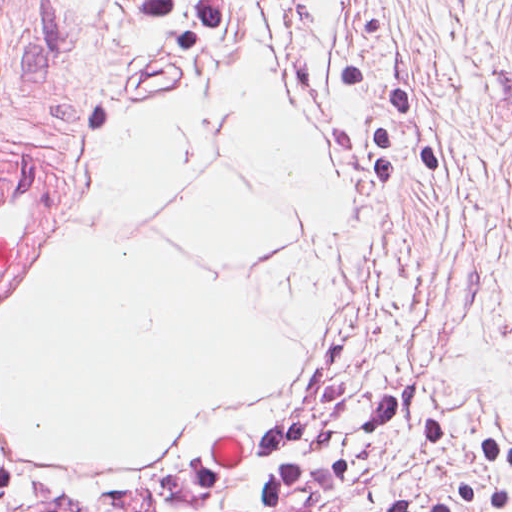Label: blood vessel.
Here are the masks:
<instances>
[{
    "label": "blood vessel",
    "mask_w": 512,
    "mask_h": 512,
    "mask_svg": "<svg viewBox=\"0 0 512 512\" xmlns=\"http://www.w3.org/2000/svg\"><path fill=\"white\" fill-rule=\"evenodd\" d=\"M46 178L47 162L37 152L0 175V277L39 209Z\"/></svg>",
    "instance_id": "1"
}]
</instances>
